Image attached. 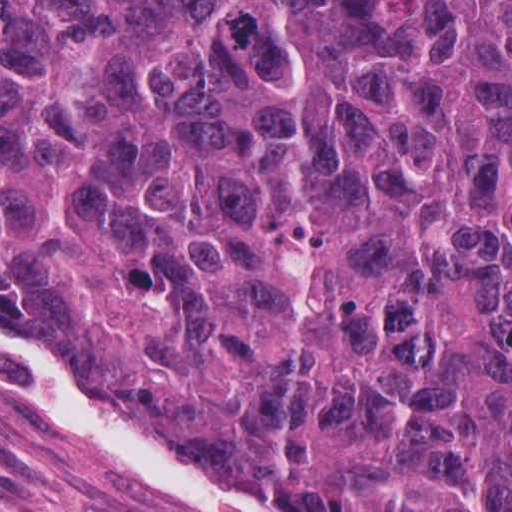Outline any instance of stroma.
I'll list each match as a JSON object with an SVG mask.
<instances>
[{"mask_svg":"<svg viewBox=\"0 0 512 512\" xmlns=\"http://www.w3.org/2000/svg\"><path fill=\"white\" fill-rule=\"evenodd\" d=\"M148 512L96 475L55 419L0 369V512Z\"/></svg>","mask_w":512,"mask_h":512,"instance_id":"35a3bbf8","label":"stroma"}]
</instances>
